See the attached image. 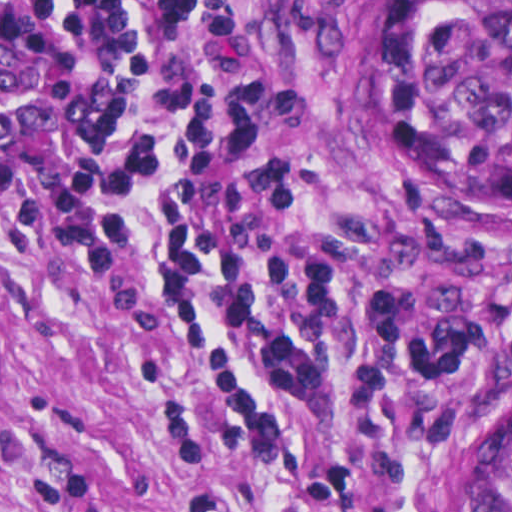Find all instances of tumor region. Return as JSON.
I'll return each mask as SVG.
<instances>
[{
	"label": "tumor region",
	"mask_w": 512,
	"mask_h": 512,
	"mask_svg": "<svg viewBox=\"0 0 512 512\" xmlns=\"http://www.w3.org/2000/svg\"><path fill=\"white\" fill-rule=\"evenodd\" d=\"M409 169L461 230L512 232V0H404L396 63ZM478 512H512V382L482 427Z\"/></svg>",
	"instance_id": "obj_1"
}]
</instances>
